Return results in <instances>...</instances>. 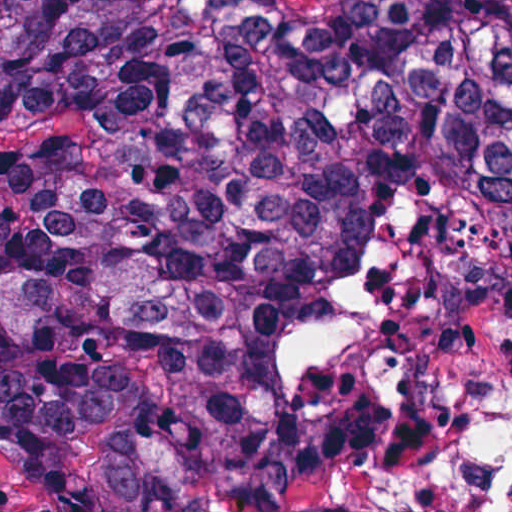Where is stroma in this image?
<instances>
[{"label":"stroma","instance_id":"35a3bbf8","mask_svg":"<svg viewBox=\"0 0 512 512\" xmlns=\"http://www.w3.org/2000/svg\"><path fill=\"white\" fill-rule=\"evenodd\" d=\"M381 512H512V322L477 335L475 360L444 379L442 420L412 428L375 468ZM0 512H48L0 462Z\"/></svg>","mask_w":512,"mask_h":512}]
</instances>
